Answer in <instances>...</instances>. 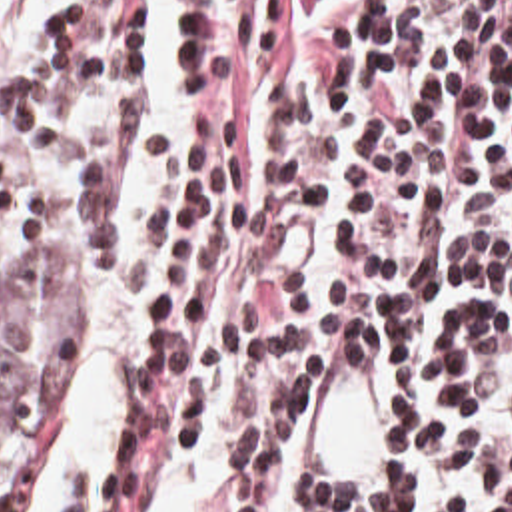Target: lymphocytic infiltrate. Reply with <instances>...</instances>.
<instances>
[{
  "instance_id": "lymphocytic-infiltrate-1",
  "label": "lymphocytic infiltrate",
  "mask_w": 512,
  "mask_h": 512,
  "mask_svg": "<svg viewBox=\"0 0 512 512\" xmlns=\"http://www.w3.org/2000/svg\"><path fill=\"white\" fill-rule=\"evenodd\" d=\"M180 31L118 466L78 512H142L172 450L224 432L240 512H512V0H180ZM144 79L146 0L57 1L39 57L0 75L94 275L118 261ZM0 271L47 291L43 203L1 157ZM364 323L394 460L312 494L302 401Z\"/></svg>"
}]
</instances>
